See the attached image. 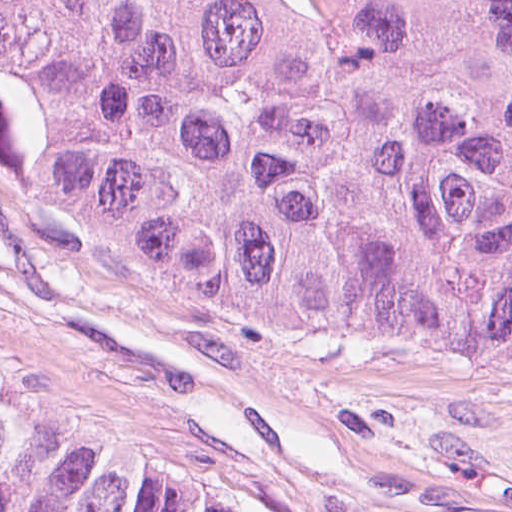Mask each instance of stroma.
I'll return each mask as SVG.
<instances>
[{
	"mask_svg": "<svg viewBox=\"0 0 512 512\" xmlns=\"http://www.w3.org/2000/svg\"><path fill=\"white\" fill-rule=\"evenodd\" d=\"M0 381L219 512H512V363L183 303L1 173Z\"/></svg>",
	"mask_w": 512,
	"mask_h": 512,
	"instance_id": "obj_1",
	"label": "stroma"
}]
</instances>
